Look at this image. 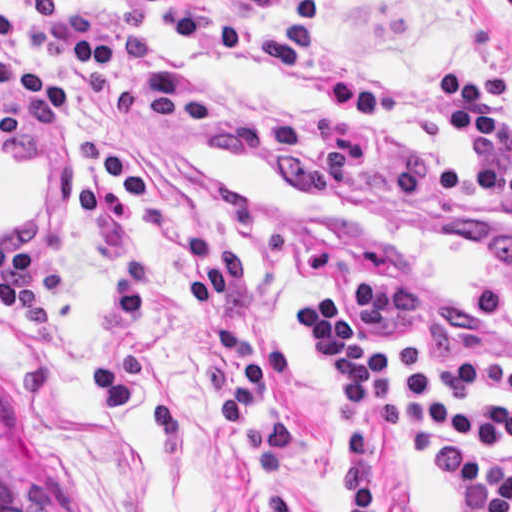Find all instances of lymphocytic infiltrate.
Returning <instances> with one entry per match:
<instances>
[{"instance_id":"lymphocytic-infiltrate-1","label":"lymphocytic infiltrate","mask_w":512,"mask_h":512,"mask_svg":"<svg viewBox=\"0 0 512 512\" xmlns=\"http://www.w3.org/2000/svg\"><path fill=\"white\" fill-rule=\"evenodd\" d=\"M139 11L177 41L233 63L304 79L324 105L322 122L289 108L255 107L203 89L169 62L149 37L123 24L77 14L53 31L51 51L81 69L87 106L103 108L81 142V211L109 248V300L102 349L92 371L95 405L119 414L139 398L137 342L155 294L128 243L135 212L164 239L185 283L200 337V362L220 387L228 432L258 512H296L298 426L279 386L294 374L289 344L256 339L225 319L228 299L246 305V264L228 244L183 229L146 189L114 127L125 115L197 123L209 144L284 176L304 197H335L361 184L374 166L363 126L423 118L465 153L459 169L433 156H399L387 165L386 195L394 204L415 190H462L473 198L512 204V79L444 69L437 96H405L321 55L324 0H210L195 18L184 0H100ZM56 0H19L29 22L49 16ZM11 24L0 9V39ZM16 74L0 59V94ZM68 115L71 98L36 74L26 97L0 106V147L23 141L29 110ZM512 229L491 232L473 303V317L492 324L509 315ZM326 366L323 383L337 433V464L329 512H377L370 492L372 437H400L418 448L448 493L455 512H512V404L476 408L438 391L427 375V351L406 345L384 351L365 345L338 303L318 288L295 312Z\"/></svg>"}]
</instances>
